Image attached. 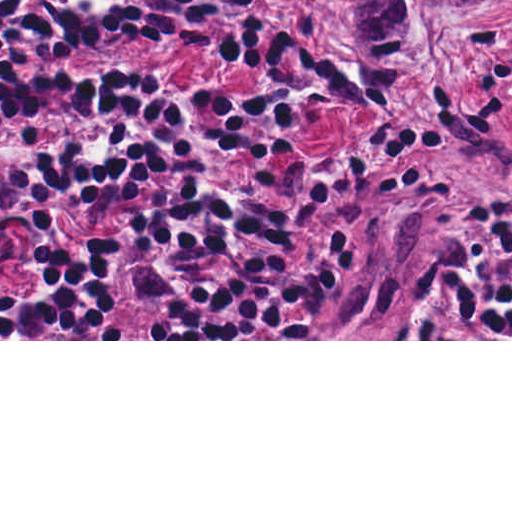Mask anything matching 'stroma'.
<instances>
[{
	"label": "stroma",
	"instance_id": "1",
	"mask_svg": "<svg viewBox=\"0 0 512 512\" xmlns=\"http://www.w3.org/2000/svg\"><path fill=\"white\" fill-rule=\"evenodd\" d=\"M44 0H25L0 18L8 30ZM190 9L231 3L210 25L199 50L167 49L117 38L72 62L69 70L126 74L174 96L188 94L185 143L211 183L232 192L283 194L291 191V167L321 163L354 144L352 122L334 102H313L295 118L284 148L240 151L215 137L210 120L214 93L246 94L262 87L256 71L227 66L225 51L241 28L263 25L293 40L310 57L334 48L339 71L360 96L366 119L398 113L436 93L455 70L466 46L486 25L512 46V0H431L397 57H382L359 43L345 20L317 0L323 22L306 0H186ZM4 56L0 55V59ZM365 66H382L402 87L387 97L365 88ZM512 143V70L472 115L445 136L430 141L388 196L387 184L369 179L320 202L301 226L287 262L294 269L343 234L362 239L337 297L313 326L290 339H158V306L139 295L134 270H125L109 290V320L126 339H0V341H512L490 337L463 319L447 297V278L461 273L494 277L500 228L512 221V156L484 177L462 187L421 226L365 266L366 254L390 221L398 201L420 171L487 127ZM106 228L104 218H66L52 230L11 236L8 261L0 266V301L25 280L34 255ZM431 318L446 339H386L396 325ZM309 335V339L306 337Z\"/></svg>",
	"mask_w": 512,
	"mask_h": 512
}]
</instances>
